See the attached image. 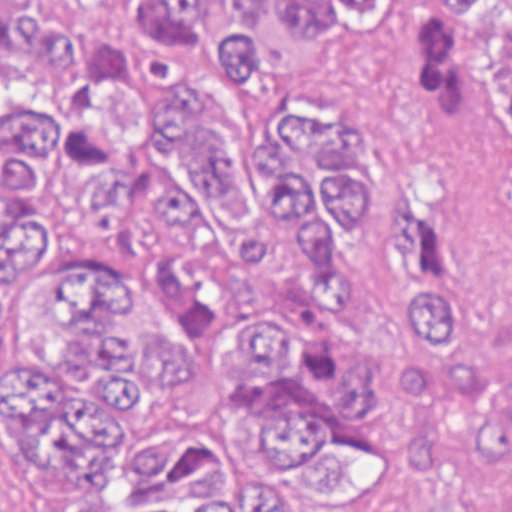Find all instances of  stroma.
Instances as JSON below:
<instances>
[{"label": "stroma", "mask_w": 512, "mask_h": 512, "mask_svg": "<svg viewBox=\"0 0 512 512\" xmlns=\"http://www.w3.org/2000/svg\"><path fill=\"white\" fill-rule=\"evenodd\" d=\"M431 0H392L378 35L340 43L306 68L265 87L261 107H354L383 143V195L350 244V294L374 329L354 388L373 454L361 488L339 499L281 487L276 512H407L405 433L394 416V381L408 349L384 309L403 286L384 264L388 199L397 185L445 197L460 212L470 248L488 277L512 298V172L463 144L432 136L423 122L426 24Z\"/></svg>", "instance_id": "1"}]
</instances>
